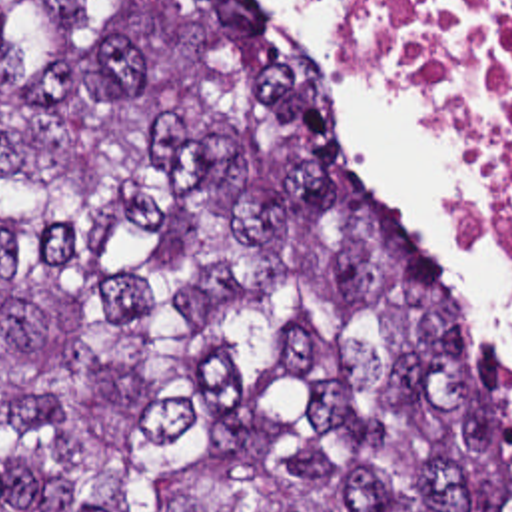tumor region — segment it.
<instances>
[{"label":"tumor region","mask_w":512,"mask_h":512,"mask_svg":"<svg viewBox=\"0 0 512 512\" xmlns=\"http://www.w3.org/2000/svg\"><path fill=\"white\" fill-rule=\"evenodd\" d=\"M229 0H0V512H512L484 339Z\"/></svg>","instance_id":"tumor-region-1"}]
</instances>
